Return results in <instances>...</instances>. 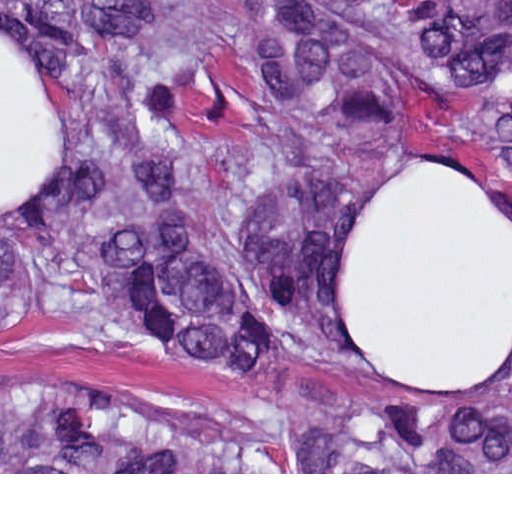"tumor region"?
I'll return each mask as SVG.
<instances>
[{
  "label": "tumor region",
  "instance_id": "obj_1",
  "mask_svg": "<svg viewBox=\"0 0 512 512\" xmlns=\"http://www.w3.org/2000/svg\"><path fill=\"white\" fill-rule=\"evenodd\" d=\"M26 1L75 191L0 223V328L81 321L327 406L260 457L42 381L0 394V472H512V360L422 386L363 364L342 303L353 217L400 165L512 226V0Z\"/></svg>",
  "mask_w": 512,
  "mask_h": 512
}]
</instances>
